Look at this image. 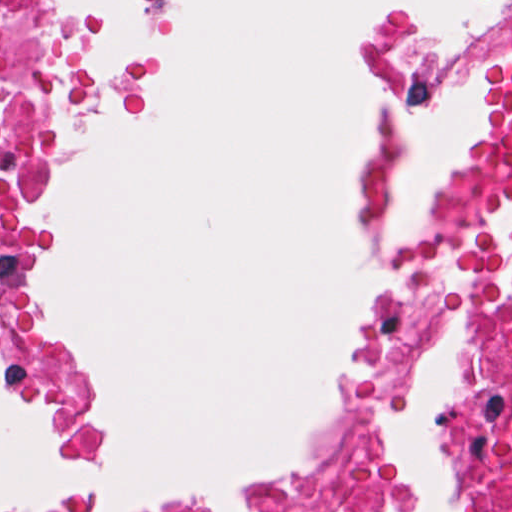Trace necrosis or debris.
Wrapping results in <instances>:
<instances>
[{
    "label": "necrosis or debris",
    "mask_w": 512,
    "mask_h": 512,
    "mask_svg": "<svg viewBox=\"0 0 512 512\" xmlns=\"http://www.w3.org/2000/svg\"><path fill=\"white\" fill-rule=\"evenodd\" d=\"M74 62L63 0H0V364L75 437L81 369L15 302ZM139 512H512V188L378 259L332 321L281 458L223 495Z\"/></svg>",
    "instance_id": "necrosis-or-debris-1"
}]
</instances>
